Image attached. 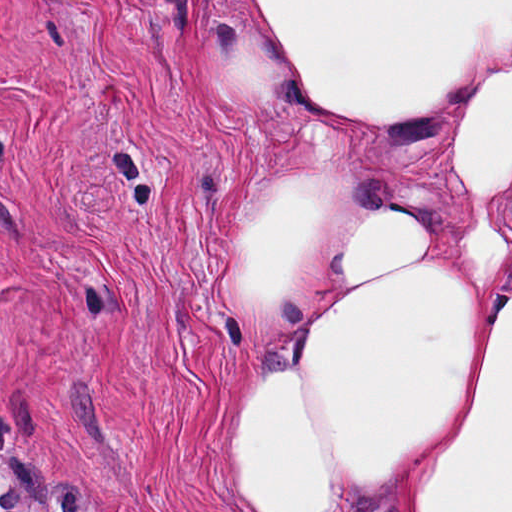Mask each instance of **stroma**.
<instances>
[{
  "label": "stroma",
  "instance_id": "1",
  "mask_svg": "<svg viewBox=\"0 0 512 512\" xmlns=\"http://www.w3.org/2000/svg\"><path fill=\"white\" fill-rule=\"evenodd\" d=\"M342 118L232 2L0 0V496L29 512H250L256 387L373 205L468 203L455 126L416 142L246 326L242 214ZM467 270L494 320L512 194Z\"/></svg>",
  "mask_w": 512,
  "mask_h": 512
}]
</instances>
